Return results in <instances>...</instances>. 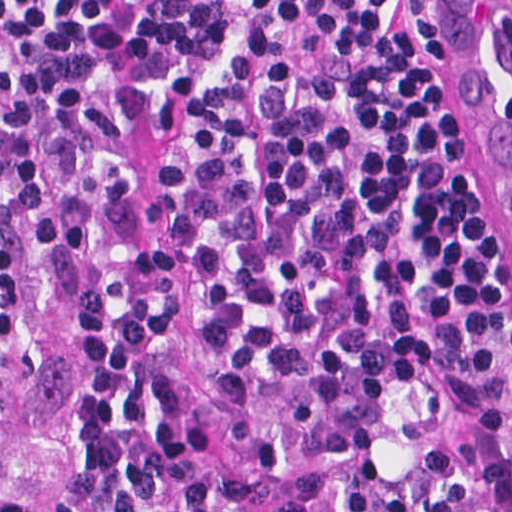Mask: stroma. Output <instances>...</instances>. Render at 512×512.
Listing matches in <instances>:
<instances>
[{
	"label": "stroma",
	"mask_w": 512,
	"mask_h": 512,
	"mask_svg": "<svg viewBox=\"0 0 512 512\" xmlns=\"http://www.w3.org/2000/svg\"><path fill=\"white\" fill-rule=\"evenodd\" d=\"M446 1V0H445ZM472 80L476 183L512 249V214L494 159L491 128ZM138 236L166 275L170 301L194 358L198 405L249 512H335L321 448L324 389L300 363L242 360L215 333L185 228L182 189L159 151L142 162ZM500 471L512 493V436L494 424ZM0 477L34 491L59 512H104L89 477V385L85 322L56 321L38 380L0 356Z\"/></svg>",
	"instance_id": "1"
}]
</instances>
